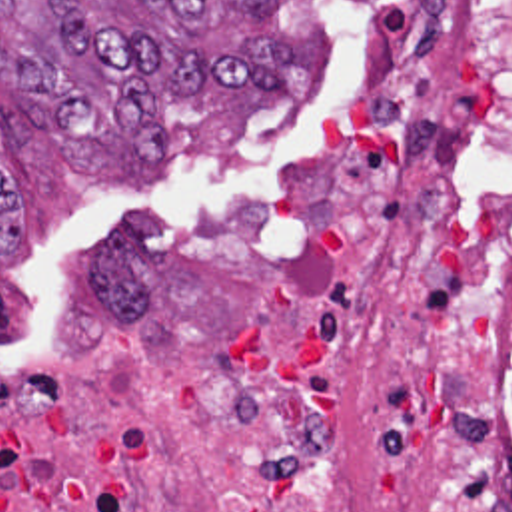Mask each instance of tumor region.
I'll return each instance as SVG.
<instances>
[{
    "label": "tumor region",
    "instance_id": "tumor-region-1",
    "mask_svg": "<svg viewBox=\"0 0 512 512\" xmlns=\"http://www.w3.org/2000/svg\"><path fill=\"white\" fill-rule=\"evenodd\" d=\"M279 0H0L1 84L53 120L63 154L163 156V110L205 90L279 96L291 40L217 38L211 18H269ZM1 140H21L0 112ZM21 240V204L0 170V252Z\"/></svg>",
    "mask_w": 512,
    "mask_h": 512
}]
</instances>
